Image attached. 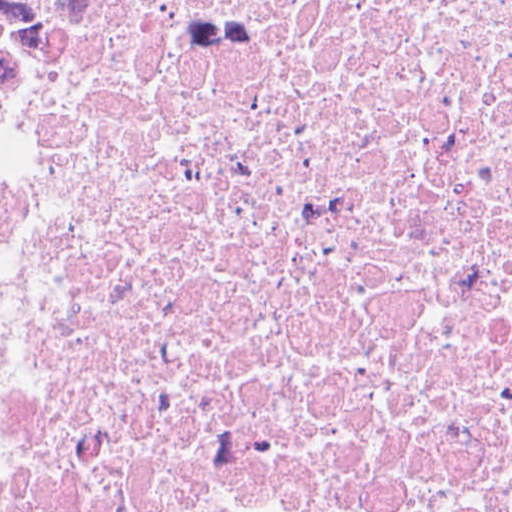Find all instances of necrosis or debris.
<instances>
[{
  "label": "necrosis or debris",
  "mask_w": 512,
  "mask_h": 512,
  "mask_svg": "<svg viewBox=\"0 0 512 512\" xmlns=\"http://www.w3.org/2000/svg\"><path fill=\"white\" fill-rule=\"evenodd\" d=\"M7 512H512V0H0Z\"/></svg>",
  "instance_id": "obj_1"
}]
</instances>
